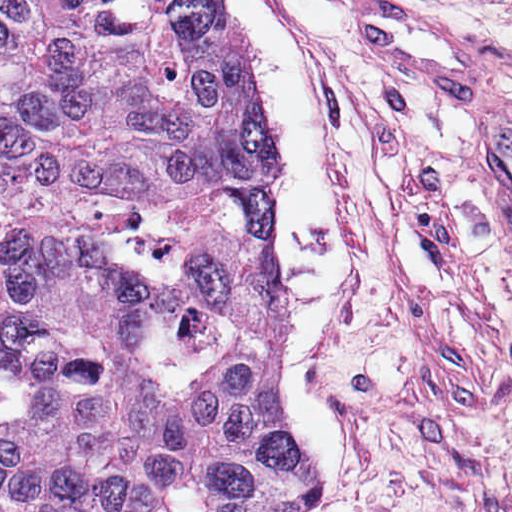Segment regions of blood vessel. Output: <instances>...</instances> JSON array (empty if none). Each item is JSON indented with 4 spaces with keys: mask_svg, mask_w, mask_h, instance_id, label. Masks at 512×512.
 Masks as SVG:
<instances>
[{
    "mask_svg": "<svg viewBox=\"0 0 512 512\" xmlns=\"http://www.w3.org/2000/svg\"><path fill=\"white\" fill-rule=\"evenodd\" d=\"M424 6L350 22L361 38L403 62L440 94L468 97L456 135L491 221L512 248V98H478L486 63L467 34Z\"/></svg>",
    "mask_w": 512,
    "mask_h": 512,
    "instance_id": "8fb6f2fc",
    "label": "blood vessel"
}]
</instances>
